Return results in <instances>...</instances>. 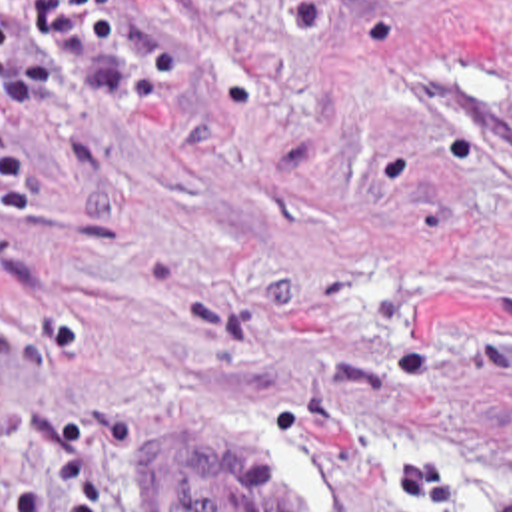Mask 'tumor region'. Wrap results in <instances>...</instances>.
I'll return each mask as SVG.
<instances>
[{
    "label": "tumor region",
    "mask_w": 512,
    "mask_h": 512,
    "mask_svg": "<svg viewBox=\"0 0 512 512\" xmlns=\"http://www.w3.org/2000/svg\"><path fill=\"white\" fill-rule=\"evenodd\" d=\"M137 487L147 512H293L287 491L261 487L245 463L205 442L147 453Z\"/></svg>",
    "instance_id": "1"
}]
</instances>
